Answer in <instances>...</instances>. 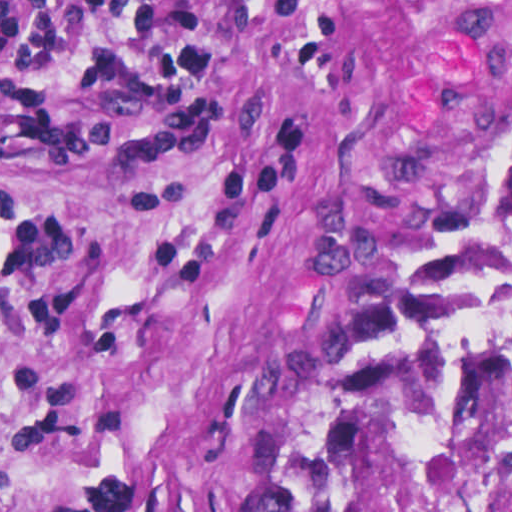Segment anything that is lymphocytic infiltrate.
<instances>
[{
	"label": "lymphocytic infiltrate",
	"instance_id": "lymphocytic-infiltrate-1",
	"mask_svg": "<svg viewBox=\"0 0 512 512\" xmlns=\"http://www.w3.org/2000/svg\"><path fill=\"white\" fill-rule=\"evenodd\" d=\"M56 386H10L2 385L1 391L19 398H49Z\"/></svg>",
	"mask_w": 512,
	"mask_h": 512
}]
</instances>
